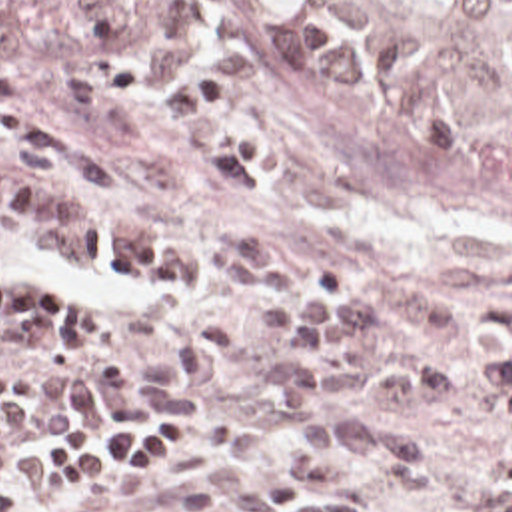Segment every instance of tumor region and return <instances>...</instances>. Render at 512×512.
Returning <instances> with one entry per match:
<instances>
[{"label": "tumor region", "instance_id": "tumor-region-1", "mask_svg": "<svg viewBox=\"0 0 512 512\" xmlns=\"http://www.w3.org/2000/svg\"><path fill=\"white\" fill-rule=\"evenodd\" d=\"M299 69L375 137L512 173V0H275Z\"/></svg>", "mask_w": 512, "mask_h": 512}]
</instances>
